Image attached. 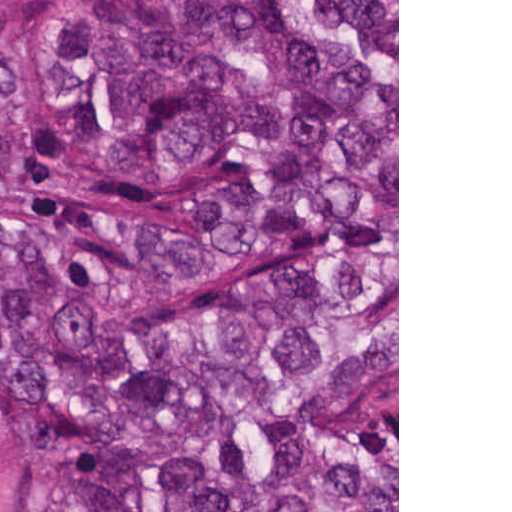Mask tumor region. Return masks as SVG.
Wrapping results in <instances>:
<instances>
[{"mask_svg":"<svg viewBox=\"0 0 512 512\" xmlns=\"http://www.w3.org/2000/svg\"><path fill=\"white\" fill-rule=\"evenodd\" d=\"M44 7L81 151L206 176L130 254L0 228V375L55 419L62 512H397V4L0 0ZM259 76H256V75ZM251 161L225 158L280 134Z\"/></svg>","mask_w":512,"mask_h":512,"instance_id":"1","label":"tumor region"}]
</instances>
